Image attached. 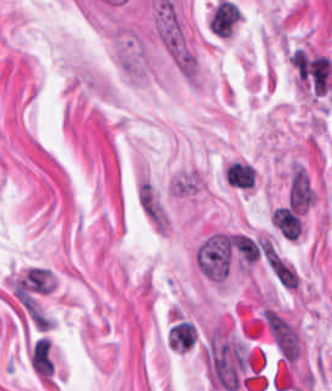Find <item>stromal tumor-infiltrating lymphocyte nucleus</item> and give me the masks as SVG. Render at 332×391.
<instances>
[{"label": "stromal tumor-infiltrating lymphocyte nucleus", "instance_id": "stromal-tumor-infiltrating-lymphocyte-nucleus-1", "mask_svg": "<svg viewBox=\"0 0 332 391\" xmlns=\"http://www.w3.org/2000/svg\"><path fill=\"white\" fill-rule=\"evenodd\" d=\"M194 339V329L191 322H177L169 331L170 348H190Z\"/></svg>", "mask_w": 332, "mask_h": 391}, {"label": "stromal tumor-infiltrating lymphocyte nucleus", "instance_id": "stromal-tumor-infiltrating-lymphocyte-nucleus-2", "mask_svg": "<svg viewBox=\"0 0 332 391\" xmlns=\"http://www.w3.org/2000/svg\"><path fill=\"white\" fill-rule=\"evenodd\" d=\"M240 16H241V11H240V8L238 6L229 36L231 35L232 31L234 30L236 24L238 23V21L240 19Z\"/></svg>", "mask_w": 332, "mask_h": 391}]
</instances>
